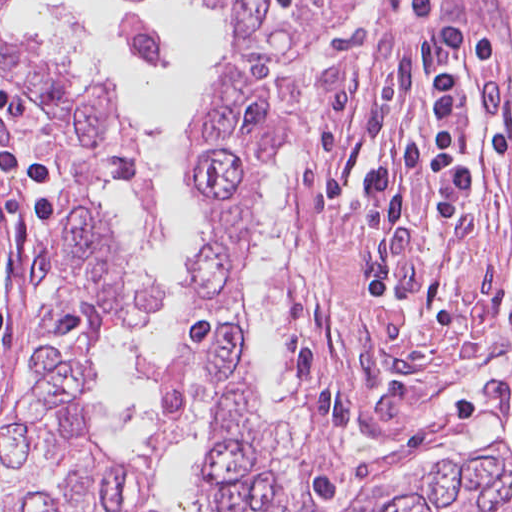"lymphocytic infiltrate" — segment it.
<instances>
[{"mask_svg": "<svg viewBox=\"0 0 512 512\" xmlns=\"http://www.w3.org/2000/svg\"><path fill=\"white\" fill-rule=\"evenodd\" d=\"M431 106L436 119L433 135H419L400 145L373 172L368 188L372 200L370 221L388 223L418 178L431 198L434 221L446 222L450 213L464 200L468 189L467 143L462 123V91L453 68L433 77L429 85ZM21 109L0 92V112ZM3 165L19 175L30 187L40 220L54 239V206L43 183V164L21 150H12L1 159ZM393 271L381 269L362 277L369 292L385 307L395 291ZM11 329L9 311L0 294V335Z\"/></svg>", "mask_w": 512, "mask_h": 512, "instance_id": "lymphocytic-infiltrate-1", "label": "lymphocytic infiltrate"}]
</instances>
